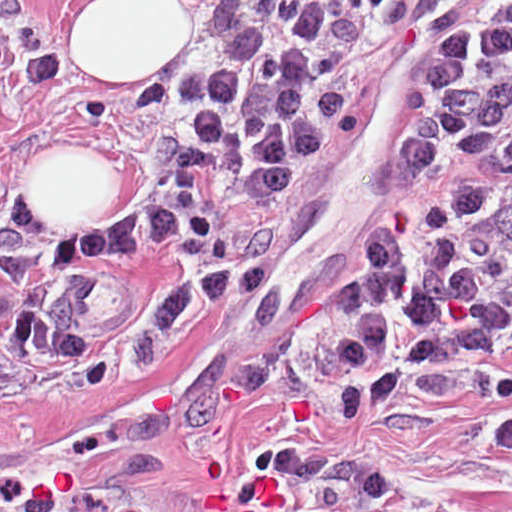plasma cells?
I'll return each instance as SVG.
<instances>
[{"label":"plasma cells","instance_id":"1","mask_svg":"<svg viewBox=\"0 0 512 512\" xmlns=\"http://www.w3.org/2000/svg\"><path fill=\"white\" fill-rule=\"evenodd\" d=\"M414 26L417 87L361 128L338 1H265L194 100L141 237L45 255L12 223L0 374H51L219 289L375 130L389 164L319 278L317 347L397 383L512 369V1H414Z\"/></svg>","mask_w":512,"mask_h":512}]
</instances>
